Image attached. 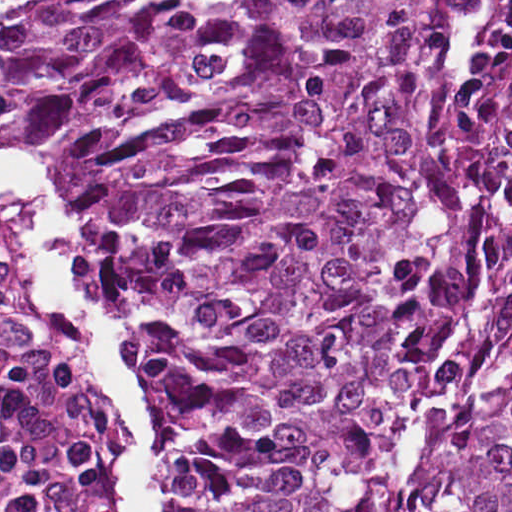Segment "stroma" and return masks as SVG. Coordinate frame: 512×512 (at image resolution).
Wrapping results in <instances>:
<instances>
[{"label": "stroma", "mask_w": 512, "mask_h": 512, "mask_svg": "<svg viewBox=\"0 0 512 512\" xmlns=\"http://www.w3.org/2000/svg\"><path fill=\"white\" fill-rule=\"evenodd\" d=\"M259 2L231 0L205 59L167 84L66 88L0 79V149L41 158L62 179L77 274L109 309L114 350L154 408L143 448L149 512H172L176 386L112 301L87 204L108 168L218 115L233 88L243 28ZM0 391L42 435L41 477L28 512H135L128 461L137 444L120 415L105 353L1 177Z\"/></svg>", "instance_id": "stroma-1"}]
</instances>
